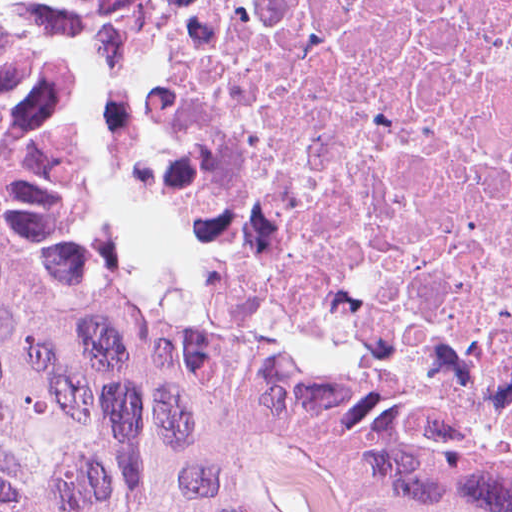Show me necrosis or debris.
I'll return each mask as SVG.
<instances>
[{"mask_svg":"<svg viewBox=\"0 0 512 512\" xmlns=\"http://www.w3.org/2000/svg\"><path fill=\"white\" fill-rule=\"evenodd\" d=\"M99 150L234 348L512 463V0H142Z\"/></svg>","mask_w":512,"mask_h":512,"instance_id":"4bbe7bcc","label":"necrosis or debris"}]
</instances>
